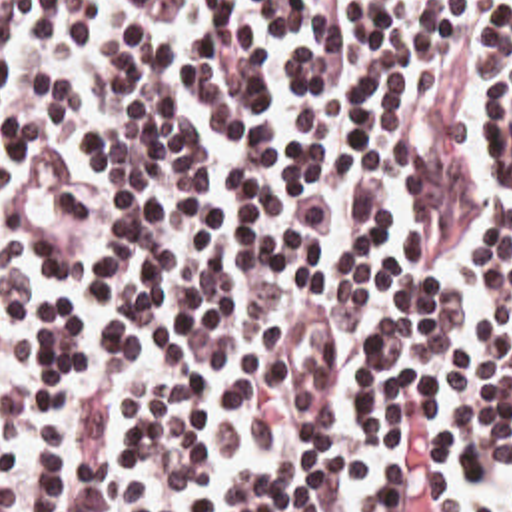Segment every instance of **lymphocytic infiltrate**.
Here are the masks:
<instances>
[{
  "mask_svg": "<svg viewBox=\"0 0 512 512\" xmlns=\"http://www.w3.org/2000/svg\"><path fill=\"white\" fill-rule=\"evenodd\" d=\"M0 512H512V0H0Z\"/></svg>",
  "mask_w": 512,
  "mask_h": 512,
  "instance_id": "lymphocytic-infiltrate-1",
  "label": "lymphocytic infiltrate"
}]
</instances>
